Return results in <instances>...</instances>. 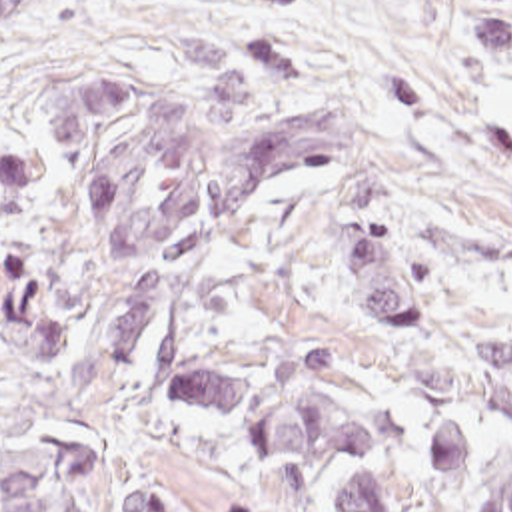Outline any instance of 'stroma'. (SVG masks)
I'll use <instances>...</instances> for the list:
<instances>
[{"mask_svg":"<svg viewBox=\"0 0 512 512\" xmlns=\"http://www.w3.org/2000/svg\"><path fill=\"white\" fill-rule=\"evenodd\" d=\"M124 76L214 128V84L252 76L254 132L288 110L356 112L415 222L512 230V0H306L242 18L234 0H20L0 24V447L92 437L168 473L182 512H332L304 471L246 455L232 427L158 404L154 380L104 366L118 300L68 206L44 130L74 80ZM417 332L376 334L332 284L326 196L308 170L258 206L222 274L218 324L360 354L401 406L388 459L401 512H435L427 419L491 415L512 439V376L473 370V342L512 340V268H443ZM168 473H166V469Z\"/></svg>","mask_w":512,"mask_h":512,"instance_id":"obj_1","label":"stroma"}]
</instances>
